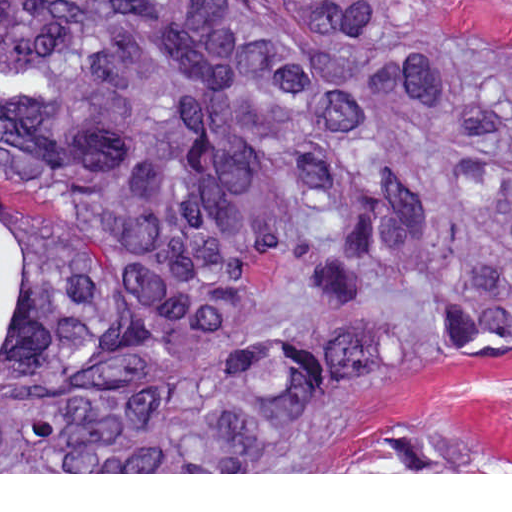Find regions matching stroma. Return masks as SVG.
I'll use <instances>...</instances> for the list:
<instances>
[{"instance_id":"stroma-1","label":"stroma","mask_w":512,"mask_h":512,"mask_svg":"<svg viewBox=\"0 0 512 512\" xmlns=\"http://www.w3.org/2000/svg\"><path fill=\"white\" fill-rule=\"evenodd\" d=\"M443 37L512 48V0H416ZM457 428L486 440L491 472H0V474H512V362L464 364L424 372L387 387L357 408L329 437L349 457L367 444L411 430Z\"/></svg>"}]
</instances>
